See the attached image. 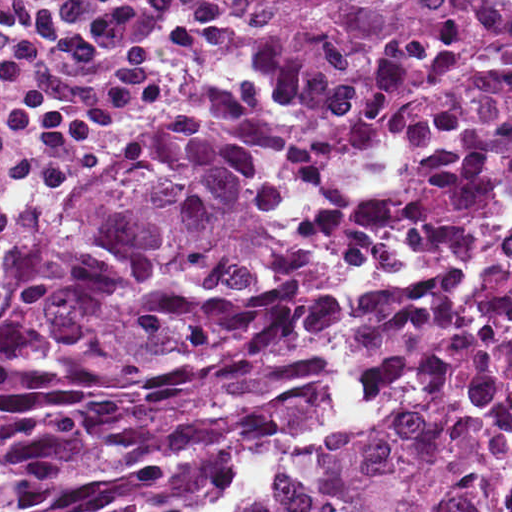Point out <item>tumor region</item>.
<instances>
[{"mask_svg": "<svg viewBox=\"0 0 512 512\" xmlns=\"http://www.w3.org/2000/svg\"><path fill=\"white\" fill-rule=\"evenodd\" d=\"M512 191V0H270L207 119L0 284V512H512V232L339 302Z\"/></svg>", "mask_w": 512, "mask_h": 512, "instance_id": "obj_1", "label": "tumor region"}]
</instances>
